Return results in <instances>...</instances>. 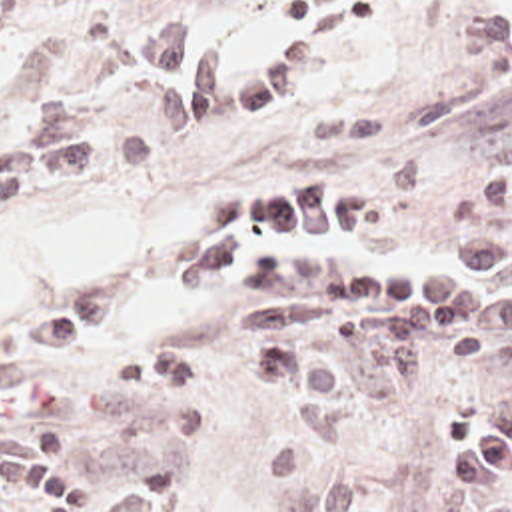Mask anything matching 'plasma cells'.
Wrapping results in <instances>:
<instances>
[{
	"label": "plasma cells",
	"instance_id": "plasma-cells-1",
	"mask_svg": "<svg viewBox=\"0 0 512 512\" xmlns=\"http://www.w3.org/2000/svg\"><path fill=\"white\" fill-rule=\"evenodd\" d=\"M159 2L145 60L155 76L163 128L238 122L298 92V72L356 36L376 0H306L282 8L302 34L266 62L208 44L190 0ZM151 160L135 134H89L69 102L35 112L21 144L0 150V208L33 190L77 188L101 170L127 172ZM368 196L330 184L236 190L214 206L202 250L177 264L183 292L228 288L242 296L246 330L334 326L330 340L280 336L242 350L246 388L286 402V424L266 442L264 474L318 480L282 512H392L388 492L358 458L364 414L414 390L442 362L470 370L512 366V240L484 238L458 254L452 272L406 260L324 252L256 236L360 234L378 226ZM117 328L103 310H75L23 328L0 366V512H161L198 482L190 462H143L115 474L69 472L75 428L95 410L194 390L181 354L107 360L83 382L51 392L39 378ZM442 450L430 476L444 492H482L512 482V386L434 418Z\"/></svg>",
	"mask_w": 512,
	"mask_h": 512
}]
</instances>
